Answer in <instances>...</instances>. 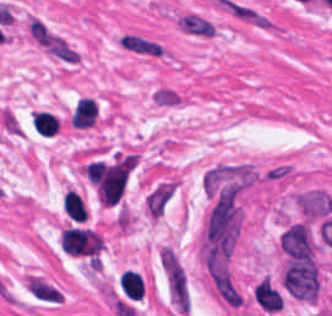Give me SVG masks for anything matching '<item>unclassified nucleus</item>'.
<instances>
[{
    "instance_id": "unclassified-nucleus-1",
    "label": "unclassified nucleus",
    "mask_w": 332,
    "mask_h": 316,
    "mask_svg": "<svg viewBox=\"0 0 332 316\" xmlns=\"http://www.w3.org/2000/svg\"><path fill=\"white\" fill-rule=\"evenodd\" d=\"M205 274L219 300L232 310L246 307V297L229 258L208 252L204 260Z\"/></svg>"
}]
</instances>
